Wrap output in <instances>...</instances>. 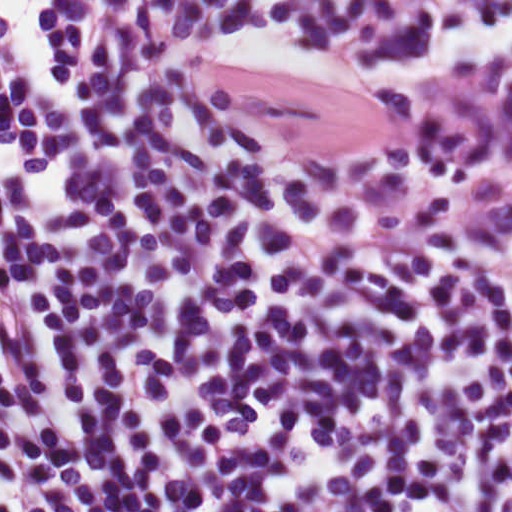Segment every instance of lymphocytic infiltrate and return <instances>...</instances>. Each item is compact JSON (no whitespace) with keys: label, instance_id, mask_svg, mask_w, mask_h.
<instances>
[{"label":"lymphocytic infiltrate","instance_id":"f902f5d3","mask_svg":"<svg viewBox=\"0 0 512 512\" xmlns=\"http://www.w3.org/2000/svg\"><path fill=\"white\" fill-rule=\"evenodd\" d=\"M0 512H512V0H0Z\"/></svg>","mask_w":512,"mask_h":512}]
</instances>
